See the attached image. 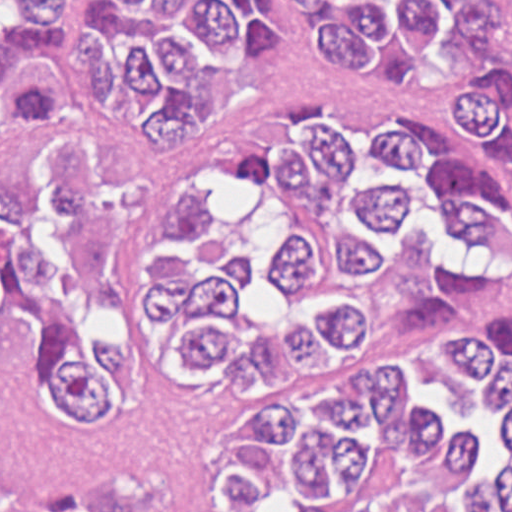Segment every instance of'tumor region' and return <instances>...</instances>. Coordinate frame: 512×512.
I'll return each mask as SVG.
<instances>
[{
  "mask_svg": "<svg viewBox=\"0 0 512 512\" xmlns=\"http://www.w3.org/2000/svg\"><path fill=\"white\" fill-rule=\"evenodd\" d=\"M511 275L512 0H0V389L226 381L213 512H512Z\"/></svg>",
  "mask_w": 512,
  "mask_h": 512,
  "instance_id": "tumor-region-1",
  "label": "tumor region"
}]
</instances>
